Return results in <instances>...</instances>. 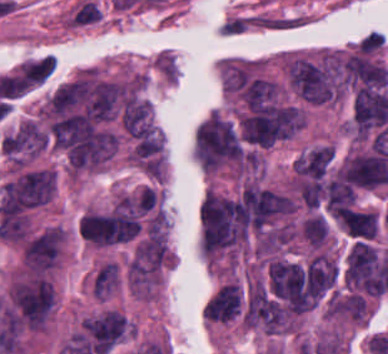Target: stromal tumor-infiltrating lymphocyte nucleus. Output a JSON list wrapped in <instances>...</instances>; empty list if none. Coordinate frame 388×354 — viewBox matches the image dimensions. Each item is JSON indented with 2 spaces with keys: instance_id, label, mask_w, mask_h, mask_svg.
<instances>
[{
  "instance_id": "obj_1",
  "label": "stromal tumor-infiltrating lymphocyte nucleus",
  "mask_w": 388,
  "mask_h": 354,
  "mask_svg": "<svg viewBox=\"0 0 388 354\" xmlns=\"http://www.w3.org/2000/svg\"><path fill=\"white\" fill-rule=\"evenodd\" d=\"M102 18L99 7L92 1H85L72 19L71 24H84Z\"/></svg>"
}]
</instances>
